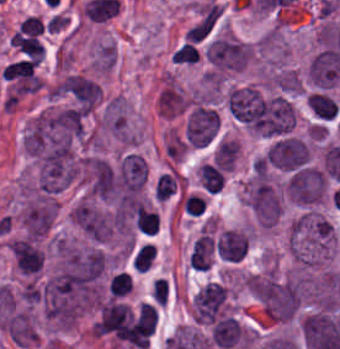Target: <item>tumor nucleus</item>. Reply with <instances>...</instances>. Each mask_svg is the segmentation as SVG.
<instances>
[{"mask_svg":"<svg viewBox=\"0 0 340 349\" xmlns=\"http://www.w3.org/2000/svg\"><path fill=\"white\" fill-rule=\"evenodd\" d=\"M70 215L79 231L93 241H105L111 234V215L104 210L78 203Z\"/></svg>","mask_w":340,"mask_h":349,"instance_id":"obj_8","label":"tumor nucleus"},{"mask_svg":"<svg viewBox=\"0 0 340 349\" xmlns=\"http://www.w3.org/2000/svg\"><path fill=\"white\" fill-rule=\"evenodd\" d=\"M266 163L291 172L311 165L310 152L300 137L278 135L269 145Z\"/></svg>","mask_w":340,"mask_h":349,"instance_id":"obj_5","label":"tumor nucleus"},{"mask_svg":"<svg viewBox=\"0 0 340 349\" xmlns=\"http://www.w3.org/2000/svg\"><path fill=\"white\" fill-rule=\"evenodd\" d=\"M54 94L78 110L92 112L101 100L97 81L79 73H66L53 87Z\"/></svg>","mask_w":340,"mask_h":349,"instance_id":"obj_3","label":"tumor nucleus"},{"mask_svg":"<svg viewBox=\"0 0 340 349\" xmlns=\"http://www.w3.org/2000/svg\"><path fill=\"white\" fill-rule=\"evenodd\" d=\"M247 207L256 224L272 227L277 221L282 203L274 185L266 178L253 177L246 185Z\"/></svg>","mask_w":340,"mask_h":349,"instance_id":"obj_2","label":"tumor nucleus"},{"mask_svg":"<svg viewBox=\"0 0 340 349\" xmlns=\"http://www.w3.org/2000/svg\"><path fill=\"white\" fill-rule=\"evenodd\" d=\"M83 184L88 195L112 200L117 193V171L105 159L88 156L83 163Z\"/></svg>","mask_w":340,"mask_h":349,"instance_id":"obj_7","label":"tumor nucleus"},{"mask_svg":"<svg viewBox=\"0 0 340 349\" xmlns=\"http://www.w3.org/2000/svg\"><path fill=\"white\" fill-rule=\"evenodd\" d=\"M215 240L209 232H202L195 240L189 253L190 267L199 269L210 268Z\"/></svg>","mask_w":340,"mask_h":349,"instance_id":"obj_13","label":"tumor nucleus"},{"mask_svg":"<svg viewBox=\"0 0 340 349\" xmlns=\"http://www.w3.org/2000/svg\"><path fill=\"white\" fill-rule=\"evenodd\" d=\"M220 113L210 104L194 106L184 126L188 147H205L219 135Z\"/></svg>","mask_w":340,"mask_h":349,"instance_id":"obj_6","label":"tumor nucleus"},{"mask_svg":"<svg viewBox=\"0 0 340 349\" xmlns=\"http://www.w3.org/2000/svg\"><path fill=\"white\" fill-rule=\"evenodd\" d=\"M248 240L245 231L224 229L216 242V253L231 260L241 259L246 252Z\"/></svg>","mask_w":340,"mask_h":349,"instance_id":"obj_12","label":"tumor nucleus"},{"mask_svg":"<svg viewBox=\"0 0 340 349\" xmlns=\"http://www.w3.org/2000/svg\"><path fill=\"white\" fill-rule=\"evenodd\" d=\"M226 298L225 286L208 282L193 297L195 322L214 323Z\"/></svg>","mask_w":340,"mask_h":349,"instance_id":"obj_11","label":"tumor nucleus"},{"mask_svg":"<svg viewBox=\"0 0 340 349\" xmlns=\"http://www.w3.org/2000/svg\"><path fill=\"white\" fill-rule=\"evenodd\" d=\"M256 296L269 318L288 321L300 297V283L267 269L256 278Z\"/></svg>","mask_w":340,"mask_h":349,"instance_id":"obj_1","label":"tumor nucleus"},{"mask_svg":"<svg viewBox=\"0 0 340 349\" xmlns=\"http://www.w3.org/2000/svg\"><path fill=\"white\" fill-rule=\"evenodd\" d=\"M289 198L298 205H311L321 201L327 192L325 169L299 167L293 169L285 183Z\"/></svg>","mask_w":340,"mask_h":349,"instance_id":"obj_4","label":"tumor nucleus"},{"mask_svg":"<svg viewBox=\"0 0 340 349\" xmlns=\"http://www.w3.org/2000/svg\"><path fill=\"white\" fill-rule=\"evenodd\" d=\"M56 217L53 200L35 199L20 211V219L26 235L43 237L50 230Z\"/></svg>","mask_w":340,"mask_h":349,"instance_id":"obj_10","label":"tumor nucleus"},{"mask_svg":"<svg viewBox=\"0 0 340 349\" xmlns=\"http://www.w3.org/2000/svg\"><path fill=\"white\" fill-rule=\"evenodd\" d=\"M252 54L249 42L216 39L205 56L215 67L241 70Z\"/></svg>","mask_w":340,"mask_h":349,"instance_id":"obj_9","label":"tumor nucleus"}]
</instances>
